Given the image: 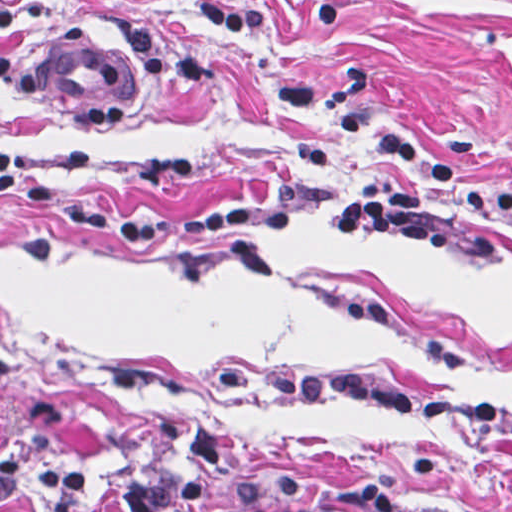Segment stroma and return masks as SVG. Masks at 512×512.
<instances>
[{
	"mask_svg": "<svg viewBox=\"0 0 512 512\" xmlns=\"http://www.w3.org/2000/svg\"><path fill=\"white\" fill-rule=\"evenodd\" d=\"M207 0H12L0 29V144L73 204L180 220L234 201L299 209L164 246L50 220L0 185V462L73 460L119 486L217 426L229 512H512V434L363 403L223 389L224 370H364L420 397L512 406V218L460 194L512 192V0L260 1L267 26L217 31ZM71 38L137 53L151 100L103 132L56 113L32 68ZM387 134L454 157L431 193L452 253L333 241L323 222L407 167ZM0 512H47L19 495Z\"/></svg>",
	"mask_w": 512,
	"mask_h": 512,
	"instance_id": "stroma-1",
	"label": "stroma"
}]
</instances>
